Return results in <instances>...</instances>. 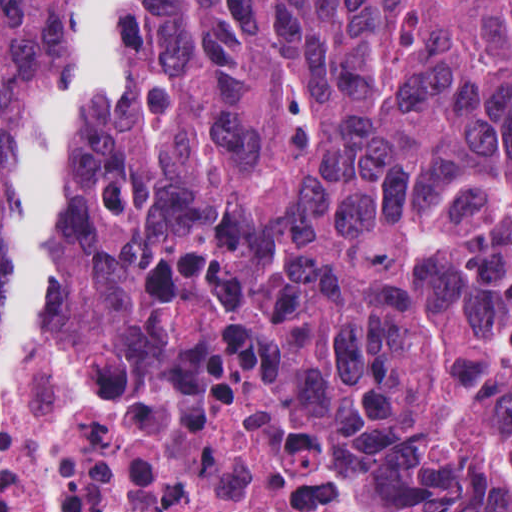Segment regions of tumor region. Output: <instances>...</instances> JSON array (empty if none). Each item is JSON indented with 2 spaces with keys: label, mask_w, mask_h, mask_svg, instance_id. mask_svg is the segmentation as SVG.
I'll return each mask as SVG.
<instances>
[{
  "label": "tumor region",
  "mask_w": 512,
  "mask_h": 512,
  "mask_svg": "<svg viewBox=\"0 0 512 512\" xmlns=\"http://www.w3.org/2000/svg\"><path fill=\"white\" fill-rule=\"evenodd\" d=\"M60 313L332 381L390 512H512V0H123Z\"/></svg>",
  "instance_id": "e687c5a6"
}]
</instances>
